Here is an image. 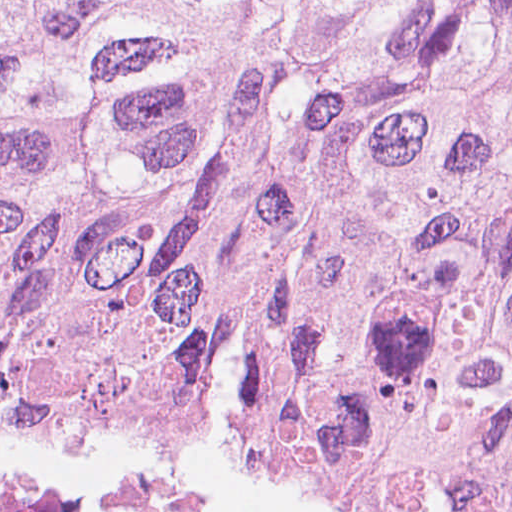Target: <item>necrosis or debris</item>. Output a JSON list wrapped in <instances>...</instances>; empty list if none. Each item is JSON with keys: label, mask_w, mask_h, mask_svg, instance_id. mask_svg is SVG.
<instances>
[{"label": "necrosis or debris", "mask_w": 512, "mask_h": 512, "mask_svg": "<svg viewBox=\"0 0 512 512\" xmlns=\"http://www.w3.org/2000/svg\"><path fill=\"white\" fill-rule=\"evenodd\" d=\"M0 512H208L160 475L0 467Z\"/></svg>", "instance_id": "necrosis-or-debris-1"}]
</instances>
